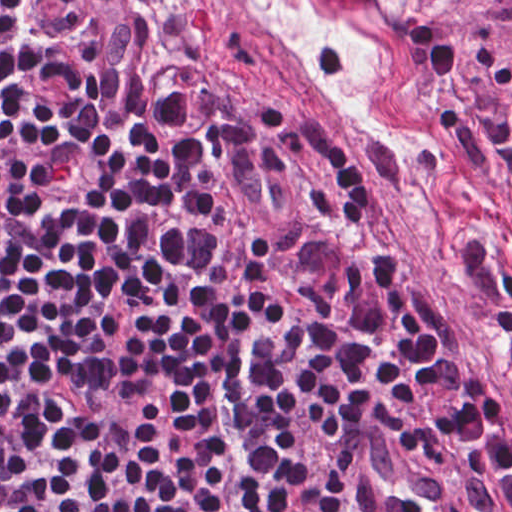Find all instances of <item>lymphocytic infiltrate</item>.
Returning a JSON list of instances; mask_svg holds the SVG:
<instances>
[{"mask_svg": "<svg viewBox=\"0 0 512 512\" xmlns=\"http://www.w3.org/2000/svg\"><path fill=\"white\" fill-rule=\"evenodd\" d=\"M492 374L331 113L160 92L139 0H0V512H369Z\"/></svg>", "mask_w": 512, "mask_h": 512, "instance_id": "obj_1", "label": "lymphocytic infiltrate"}]
</instances>
